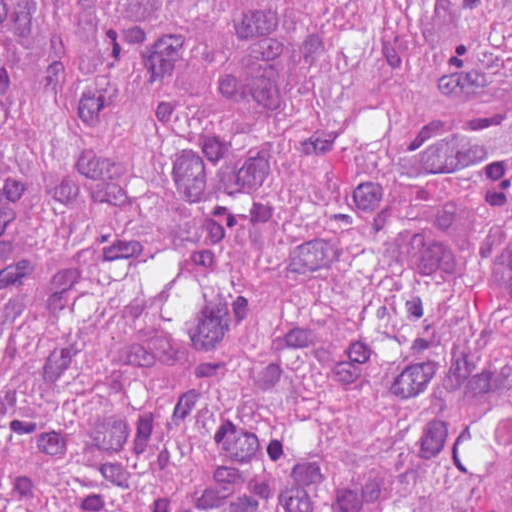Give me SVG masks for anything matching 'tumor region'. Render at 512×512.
I'll list each match as a JSON object with an SVG mask.
<instances>
[{
	"mask_svg": "<svg viewBox=\"0 0 512 512\" xmlns=\"http://www.w3.org/2000/svg\"><path fill=\"white\" fill-rule=\"evenodd\" d=\"M0 0V512H512V0Z\"/></svg>",
	"mask_w": 512,
	"mask_h": 512,
	"instance_id": "e687c5a6",
	"label": "tumor region"
}]
</instances>
